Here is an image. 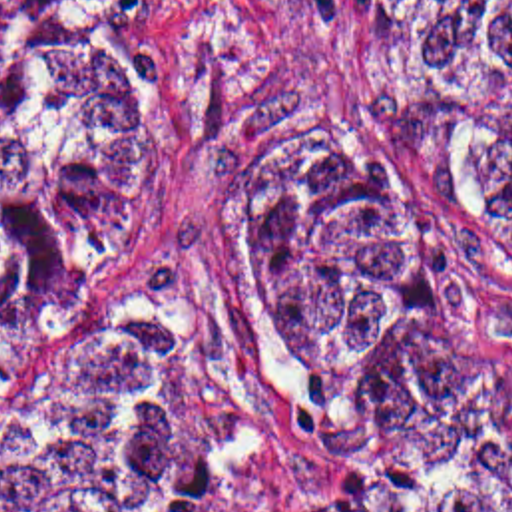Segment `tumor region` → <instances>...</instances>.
Listing matches in <instances>:
<instances>
[{"label":"tumor region","mask_w":512,"mask_h":512,"mask_svg":"<svg viewBox=\"0 0 512 512\" xmlns=\"http://www.w3.org/2000/svg\"><path fill=\"white\" fill-rule=\"evenodd\" d=\"M367 125L512 253V0H371ZM184 93L112 0H0V430H20L86 280L162 205ZM188 308L108 314L86 406L0 512H512V484L401 474L512 430V350L385 161L273 131L216 169Z\"/></svg>","instance_id":"obj_1"}]
</instances>
